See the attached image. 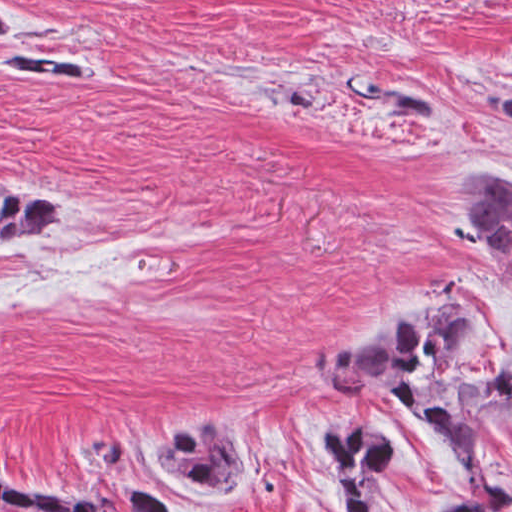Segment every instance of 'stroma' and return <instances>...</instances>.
Listing matches in <instances>:
<instances>
[{
  "instance_id": "stroma-1",
  "label": "stroma",
  "mask_w": 512,
  "mask_h": 512,
  "mask_svg": "<svg viewBox=\"0 0 512 512\" xmlns=\"http://www.w3.org/2000/svg\"><path fill=\"white\" fill-rule=\"evenodd\" d=\"M1 34V476L129 512L132 484L180 512H336L309 457L326 424L397 442L380 512L466 490L441 440L394 396L312 380L321 342L421 284L512 315V268L473 239L463 173L512 170V135L473 118L474 82L512 76V0H5ZM99 62L103 90L1 70V46ZM410 80L399 113L360 78ZM8 185L56 223L1 240ZM100 423L124 464L84 458ZM224 429L256 467L228 498L175 488L148 459ZM512 489V427L485 451ZM512 512V510L508 511Z\"/></svg>"
}]
</instances>
